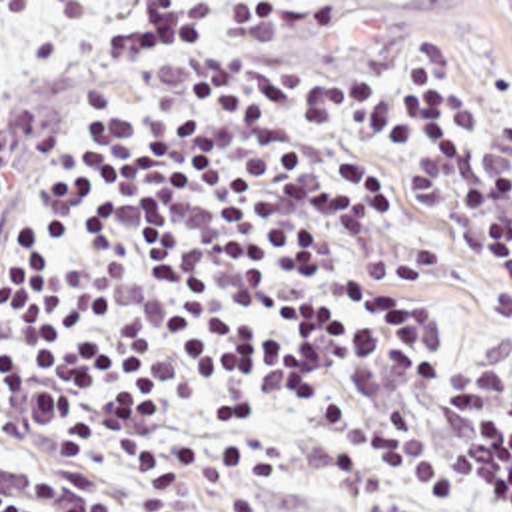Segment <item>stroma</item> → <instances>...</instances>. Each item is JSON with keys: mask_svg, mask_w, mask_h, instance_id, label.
Masks as SVG:
<instances>
[{"mask_svg": "<svg viewBox=\"0 0 512 512\" xmlns=\"http://www.w3.org/2000/svg\"><path fill=\"white\" fill-rule=\"evenodd\" d=\"M24 136L0 138V168L6 172ZM272 427L284 449V465L262 512H423L387 483L341 493L332 487L326 457L316 449L294 407L278 409ZM469 512H499L475 503Z\"/></svg>", "mask_w": 512, "mask_h": 512, "instance_id": "obj_1", "label": "stroma"}]
</instances>
